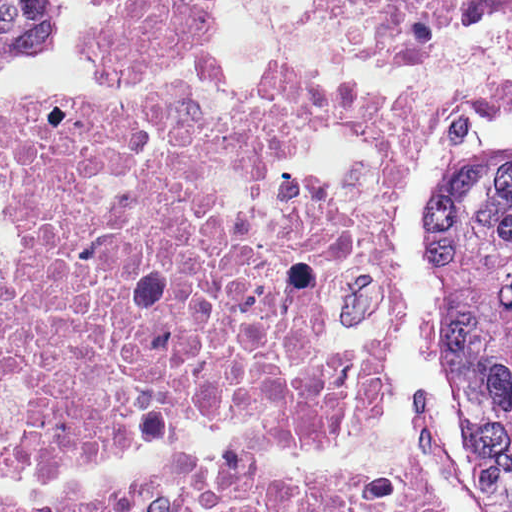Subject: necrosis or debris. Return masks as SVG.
I'll list each match as a JSON object with an SVG mask.
<instances>
[{"label":"necrosis or debris","instance_id":"obj_1","mask_svg":"<svg viewBox=\"0 0 512 512\" xmlns=\"http://www.w3.org/2000/svg\"><path fill=\"white\" fill-rule=\"evenodd\" d=\"M306 1L339 45L378 53L512 17V0ZM223 3L108 0L72 57L155 79ZM461 101L330 76L221 112L185 92L107 112L0 92L17 234L0 250V512H440L381 409L405 334L393 213Z\"/></svg>","mask_w":512,"mask_h":512}]
</instances>
